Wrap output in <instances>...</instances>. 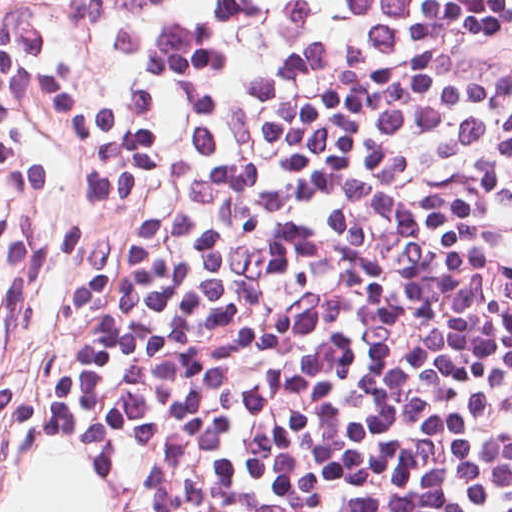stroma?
Returning a JSON list of instances; mask_svg holds the SVG:
<instances>
[{"label":"stroma","mask_w":512,"mask_h":512,"mask_svg":"<svg viewBox=\"0 0 512 512\" xmlns=\"http://www.w3.org/2000/svg\"><path fill=\"white\" fill-rule=\"evenodd\" d=\"M19 183L0 172V284L21 207ZM78 454L93 471L108 512H132L137 466L124 435L100 404L53 412L13 398L0 378V510L45 441Z\"/></svg>","instance_id":"1"}]
</instances>
